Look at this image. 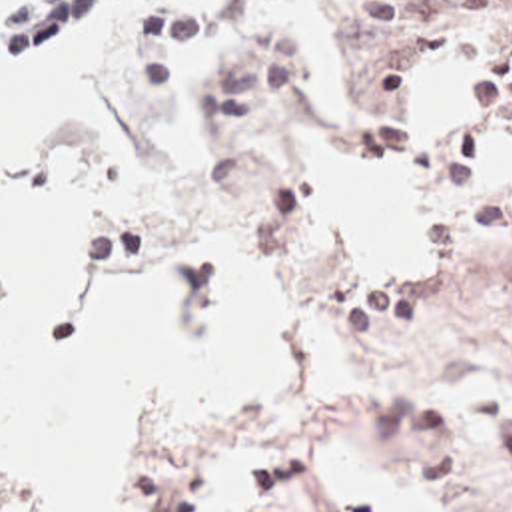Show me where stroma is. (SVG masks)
<instances>
[{
	"mask_svg": "<svg viewBox=\"0 0 512 512\" xmlns=\"http://www.w3.org/2000/svg\"><path fill=\"white\" fill-rule=\"evenodd\" d=\"M70 2L42 0L0 16V59L24 51ZM367 4L363 24L331 12L349 103L309 113L291 81V45L253 24L249 0H223L197 79L205 147L183 201L111 221L103 273L58 333L76 343L92 337L113 291L163 245L173 339L195 347L199 237L187 221L221 219L259 247L275 297L289 293L323 311L363 373L453 353L499 373L503 395L487 413L431 405L449 423L467 485L483 501H512V123L457 105L445 61L411 37L427 18L465 14L459 0ZM309 135H337L349 157L413 173L419 287H399L393 271L365 277L351 235L309 219L303 167L289 145ZM419 481L427 512L437 511ZM211 485L195 463H133L125 512H205ZM0 507L34 512L2 479ZM239 512L343 509L307 469L279 465L253 481Z\"/></svg>",
	"mask_w": 512,
	"mask_h": 512,
	"instance_id": "obj_1",
	"label": "stroma"
}]
</instances>
